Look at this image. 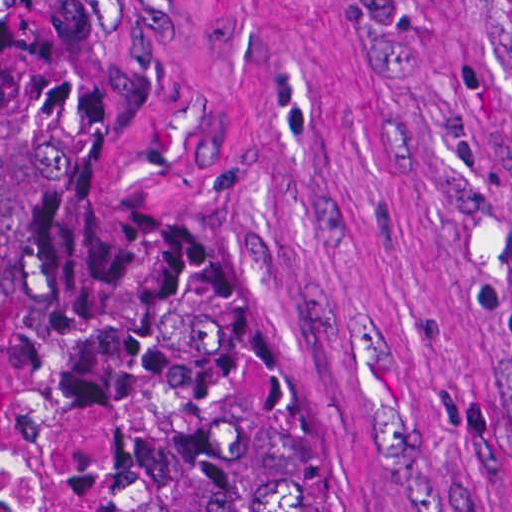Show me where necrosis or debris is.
Returning <instances> with one entry per match:
<instances>
[{"label": "necrosis or debris", "mask_w": 512, "mask_h": 512, "mask_svg": "<svg viewBox=\"0 0 512 512\" xmlns=\"http://www.w3.org/2000/svg\"><path fill=\"white\" fill-rule=\"evenodd\" d=\"M0 512H89L23 423V377L0 355Z\"/></svg>", "instance_id": "1"}]
</instances>
